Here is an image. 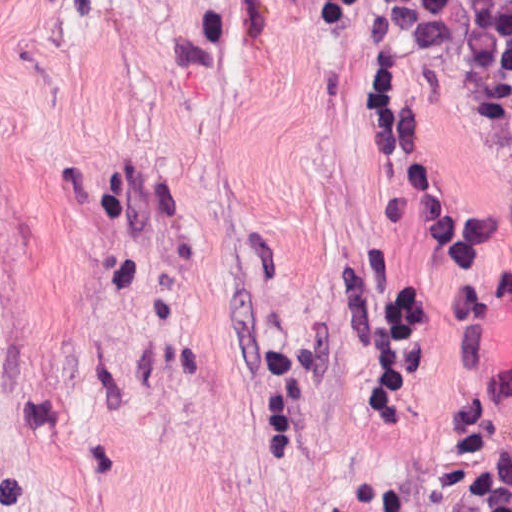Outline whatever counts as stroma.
I'll return each instance as SVG.
<instances>
[{
    "label": "stroma",
    "mask_w": 512,
    "mask_h": 512,
    "mask_svg": "<svg viewBox=\"0 0 512 512\" xmlns=\"http://www.w3.org/2000/svg\"><path fill=\"white\" fill-rule=\"evenodd\" d=\"M387 44L512 358V135L382 0H0V512H443L466 326L365 108ZM362 252L427 339L380 411L334 304ZM288 324L317 397L288 451L258 452Z\"/></svg>",
    "instance_id": "obj_1"
}]
</instances>
